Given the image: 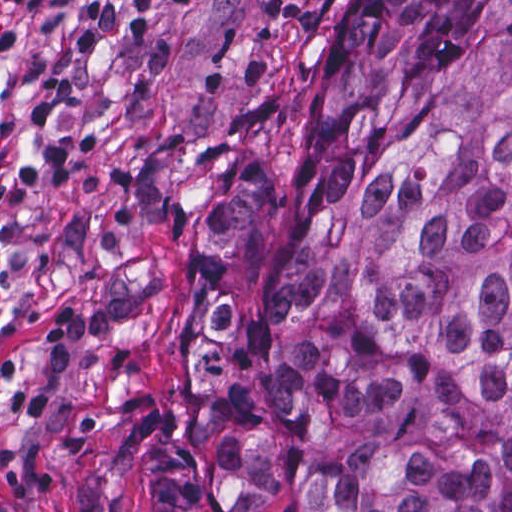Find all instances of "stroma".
Listing matches in <instances>:
<instances>
[{
	"instance_id": "stroma-1",
	"label": "stroma",
	"mask_w": 512,
	"mask_h": 512,
	"mask_svg": "<svg viewBox=\"0 0 512 512\" xmlns=\"http://www.w3.org/2000/svg\"><path fill=\"white\" fill-rule=\"evenodd\" d=\"M342 0H54L0 16V509L143 512L202 312L274 277L360 130L303 128ZM238 158L273 170L246 248H205Z\"/></svg>"
}]
</instances>
